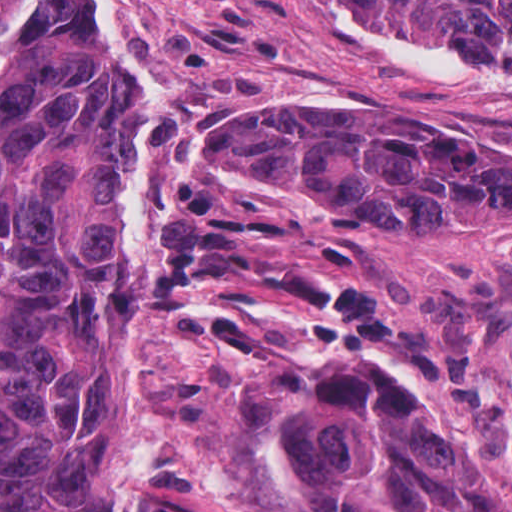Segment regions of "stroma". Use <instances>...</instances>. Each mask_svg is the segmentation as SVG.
I'll list each match as a JSON object with an SVG mask.
<instances>
[{
    "instance_id": "obj_1",
    "label": "stroma",
    "mask_w": 512,
    "mask_h": 512,
    "mask_svg": "<svg viewBox=\"0 0 512 512\" xmlns=\"http://www.w3.org/2000/svg\"><path fill=\"white\" fill-rule=\"evenodd\" d=\"M343 1L503 66L501 86L407 66L299 0H113L142 49L165 67L161 86L152 83L162 102L158 287L146 320L112 342L100 375L110 481L141 512H284L258 476L247 366L218 332L215 312L227 296L309 353L359 361L406 389L415 358L438 354L454 366L477 332L512 344V224L482 238L346 224L267 180L197 170L186 149L182 127L194 120L271 105L379 107L435 141L512 150V40L468 38L403 15L388 0ZM179 189H231L258 212L292 222L293 241L227 242L374 291V309L395 329L391 349L349 353L321 343L304 314L254 275L167 281V212Z\"/></svg>"
}]
</instances>
